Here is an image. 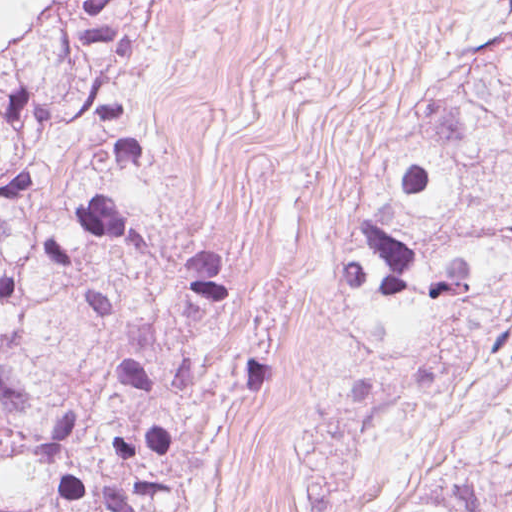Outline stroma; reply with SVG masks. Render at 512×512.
<instances>
[{
	"label": "stroma",
	"mask_w": 512,
	"mask_h": 512,
	"mask_svg": "<svg viewBox=\"0 0 512 512\" xmlns=\"http://www.w3.org/2000/svg\"><path fill=\"white\" fill-rule=\"evenodd\" d=\"M503 24L512 0L493 27ZM479 458L512 460V352L386 354L335 512H392L404 484Z\"/></svg>",
	"instance_id": "obj_1"
}]
</instances>
